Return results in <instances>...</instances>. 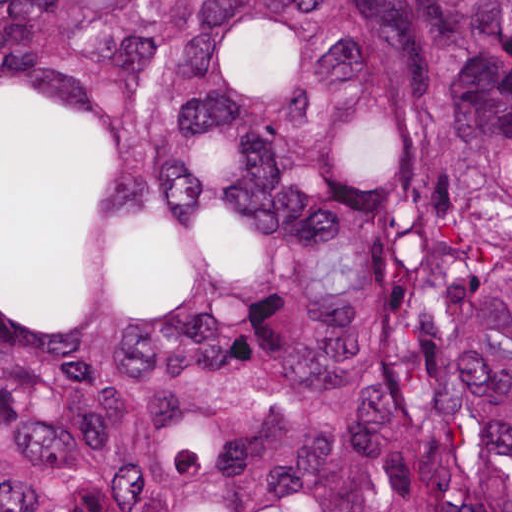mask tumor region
<instances>
[{
  "mask_svg": "<svg viewBox=\"0 0 512 512\" xmlns=\"http://www.w3.org/2000/svg\"><path fill=\"white\" fill-rule=\"evenodd\" d=\"M0 512H512V0H0Z\"/></svg>",
  "mask_w": 512,
  "mask_h": 512,
  "instance_id": "1",
  "label": "tumor region"
}]
</instances>
